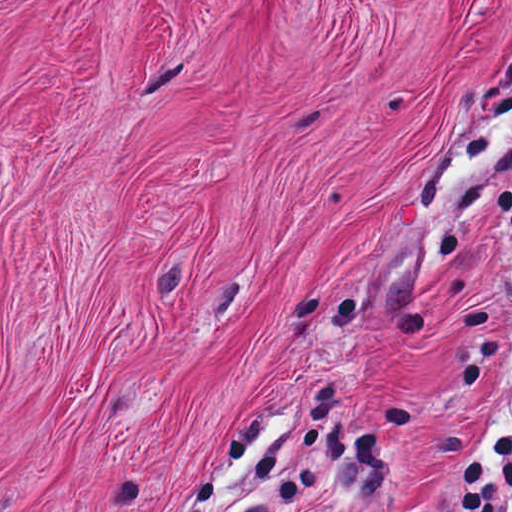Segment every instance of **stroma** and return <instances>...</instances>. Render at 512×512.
Here are the masks:
<instances>
[{"mask_svg":"<svg viewBox=\"0 0 512 512\" xmlns=\"http://www.w3.org/2000/svg\"><path fill=\"white\" fill-rule=\"evenodd\" d=\"M499 59L512 0H0V512H454L512 234L412 179Z\"/></svg>","mask_w":512,"mask_h":512,"instance_id":"obj_1","label":"stroma"}]
</instances>
